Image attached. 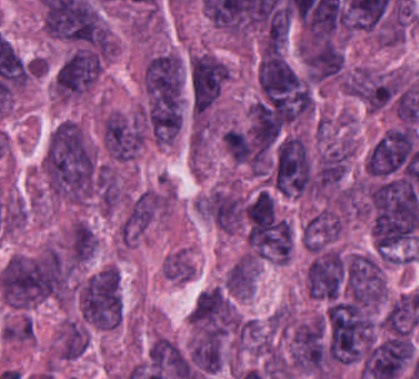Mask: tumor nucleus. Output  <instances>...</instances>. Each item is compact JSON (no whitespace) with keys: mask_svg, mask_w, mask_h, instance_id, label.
<instances>
[{"mask_svg":"<svg viewBox=\"0 0 419 379\" xmlns=\"http://www.w3.org/2000/svg\"><path fill=\"white\" fill-rule=\"evenodd\" d=\"M140 124L119 113H111L103 121V141L115 159H132L143 143Z\"/></svg>","mask_w":419,"mask_h":379,"instance_id":"feef74b5","label":"tumor nucleus"},{"mask_svg":"<svg viewBox=\"0 0 419 379\" xmlns=\"http://www.w3.org/2000/svg\"><path fill=\"white\" fill-rule=\"evenodd\" d=\"M96 248V234L87 223L77 222L72 229L70 263H83Z\"/></svg>","mask_w":419,"mask_h":379,"instance_id":"f7901128","label":"tumor nucleus"},{"mask_svg":"<svg viewBox=\"0 0 419 379\" xmlns=\"http://www.w3.org/2000/svg\"><path fill=\"white\" fill-rule=\"evenodd\" d=\"M84 318L105 328L122 321L123 300L121 276L114 266H107L85 280L80 294Z\"/></svg>","mask_w":419,"mask_h":379,"instance_id":"8643909e","label":"tumor nucleus"},{"mask_svg":"<svg viewBox=\"0 0 419 379\" xmlns=\"http://www.w3.org/2000/svg\"><path fill=\"white\" fill-rule=\"evenodd\" d=\"M346 88L371 110L392 103L400 89L397 75L358 69L346 75Z\"/></svg>","mask_w":419,"mask_h":379,"instance_id":"8087334f","label":"tumor nucleus"},{"mask_svg":"<svg viewBox=\"0 0 419 379\" xmlns=\"http://www.w3.org/2000/svg\"><path fill=\"white\" fill-rule=\"evenodd\" d=\"M190 358L201 373L218 370L222 360L221 336L217 332L205 330L192 347Z\"/></svg>","mask_w":419,"mask_h":379,"instance_id":"3e47fb67","label":"tumor nucleus"},{"mask_svg":"<svg viewBox=\"0 0 419 379\" xmlns=\"http://www.w3.org/2000/svg\"><path fill=\"white\" fill-rule=\"evenodd\" d=\"M290 359L307 371H322L329 359L324 317H316L295 327L290 343Z\"/></svg>","mask_w":419,"mask_h":379,"instance_id":"3d1891a8","label":"tumor nucleus"},{"mask_svg":"<svg viewBox=\"0 0 419 379\" xmlns=\"http://www.w3.org/2000/svg\"><path fill=\"white\" fill-rule=\"evenodd\" d=\"M98 53L75 50L59 68L56 82L61 96L71 97L90 87L100 71Z\"/></svg>","mask_w":419,"mask_h":379,"instance_id":"c2bd9aea","label":"tumor nucleus"},{"mask_svg":"<svg viewBox=\"0 0 419 379\" xmlns=\"http://www.w3.org/2000/svg\"><path fill=\"white\" fill-rule=\"evenodd\" d=\"M227 66L216 55L200 53L188 67L191 100L194 109L204 111L219 95Z\"/></svg>","mask_w":419,"mask_h":379,"instance_id":"2083b535","label":"tumor nucleus"},{"mask_svg":"<svg viewBox=\"0 0 419 379\" xmlns=\"http://www.w3.org/2000/svg\"><path fill=\"white\" fill-rule=\"evenodd\" d=\"M348 297L364 307L380 303L384 292V270L376 257L353 255L343 269Z\"/></svg>","mask_w":419,"mask_h":379,"instance_id":"5ab6c2c4","label":"tumor nucleus"},{"mask_svg":"<svg viewBox=\"0 0 419 379\" xmlns=\"http://www.w3.org/2000/svg\"><path fill=\"white\" fill-rule=\"evenodd\" d=\"M67 266L52 249L8 259L1 270V289L9 304L28 306L64 292Z\"/></svg>","mask_w":419,"mask_h":379,"instance_id":"2f306a5c","label":"tumor nucleus"},{"mask_svg":"<svg viewBox=\"0 0 419 379\" xmlns=\"http://www.w3.org/2000/svg\"><path fill=\"white\" fill-rule=\"evenodd\" d=\"M347 256L334 250L318 247L305 269L306 286L311 296L336 300L340 297Z\"/></svg>","mask_w":419,"mask_h":379,"instance_id":"2cbd58db","label":"tumor nucleus"},{"mask_svg":"<svg viewBox=\"0 0 419 379\" xmlns=\"http://www.w3.org/2000/svg\"><path fill=\"white\" fill-rule=\"evenodd\" d=\"M88 338L77 323H69L61 343V356L76 359L87 349Z\"/></svg>","mask_w":419,"mask_h":379,"instance_id":"268c6acd","label":"tumor nucleus"}]
</instances>
